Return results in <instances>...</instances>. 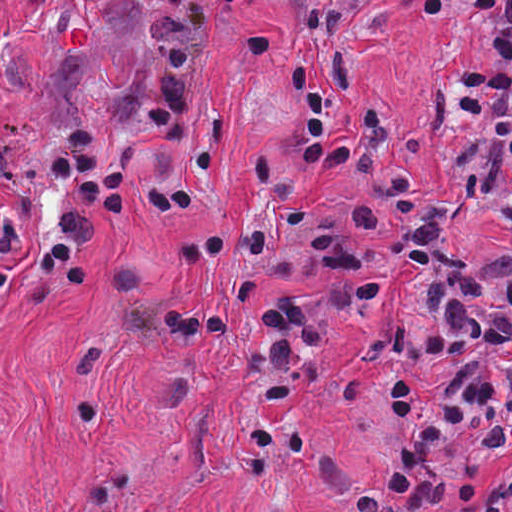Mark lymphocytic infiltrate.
<instances>
[{"mask_svg": "<svg viewBox=\"0 0 512 512\" xmlns=\"http://www.w3.org/2000/svg\"><path fill=\"white\" fill-rule=\"evenodd\" d=\"M450 4L469 31L490 39L497 59L488 78L449 93L442 164L477 211L512 231V0ZM299 80V157L379 181L406 238V303L382 337L378 379L390 421L386 465L346 501L340 456L319 452V477L350 512H512V255L456 246L446 200L427 191L403 153L399 109L345 50L299 70ZM239 113L230 101L164 130L186 166L153 187L145 216L173 222L223 182L220 146ZM128 172L129 146L0 203V305L22 285L83 284L95 247L127 214ZM247 182L324 260L369 270L365 236L388 227L386 205L324 200L291 179L275 146L255 158ZM244 220L255 273L310 279L294 254ZM168 244L172 262L196 275L226 248L218 230L199 222ZM105 271V309L136 337L199 345L220 341L232 321L225 297L164 288L145 253H120ZM323 309L274 301L239 350L242 389L259 416L299 412V368L319 360L315 320ZM0 512L9 511L0 503Z\"/></svg>", "mask_w": 512, "mask_h": 512, "instance_id": "1", "label": "lymphocytic infiltrate"}]
</instances>
